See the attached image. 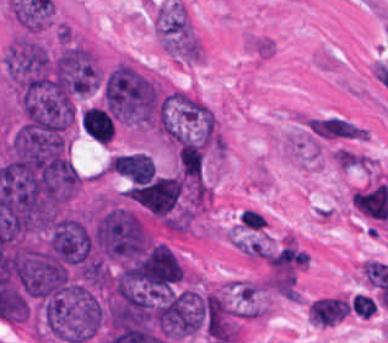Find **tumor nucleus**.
<instances>
[{"label":"tumor nucleus","instance_id":"tumor-nucleus-1","mask_svg":"<svg viewBox=\"0 0 388 343\" xmlns=\"http://www.w3.org/2000/svg\"><path fill=\"white\" fill-rule=\"evenodd\" d=\"M81 128L100 144H105L114 134V122L105 109L90 106L80 117Z\"/></svg>","mask_w":388,"mask_h":343}]
</instances>
